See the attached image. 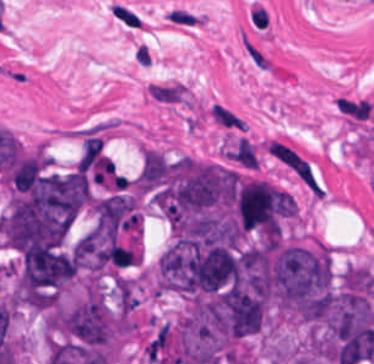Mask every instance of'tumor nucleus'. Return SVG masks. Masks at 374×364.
<instances>
[{"instance_id":"1","label":"tumor nucleus","mask_w":374,"mask_h":364,"mask_svg":"<svg viewBox=\"0 0 374 364\" xmlns=\"http://www.w3.org/2000/svg\"><path fill=\"white\" fill-rule=\"evenodd\" d=\"M148 200L172 232H214L226 222L227 169L189 155H165Z\"/></svg>"}]
</instances>
